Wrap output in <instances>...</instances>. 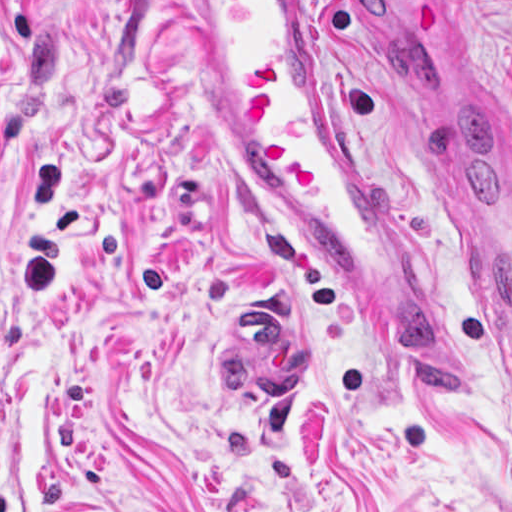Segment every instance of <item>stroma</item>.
Segmentation results:
<instances>
[{
    "label": "stroma",
    "instance_id": "obj_1",
    "mask_svg": "<svg viewBox=\"0 0 512 512\" xmlns=\"http://www.w3.org/2000/svg\"><path fill=\"white\" fill-rule=\"evenodd\" d=\"M188 1H305L470 408L252 179ZM473 151L512 189V0H0V512H512V359L438 206ZM261 295L310 343L298 402L219 353Z\"/></svg>",
    "mask_w": 512,
    "mask_h": 512
}]
</instances>
